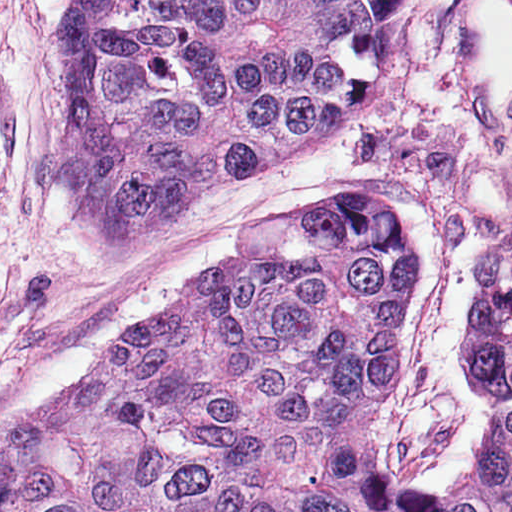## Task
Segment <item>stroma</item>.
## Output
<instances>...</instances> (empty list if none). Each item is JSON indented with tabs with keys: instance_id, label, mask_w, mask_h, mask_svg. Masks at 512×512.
<instances>
[{
	"instance_id": "obj_1",
	"label": "stroma",
	"mask_w": 512,
	"mask_h": 512,
	"mask_svg": "<svg viewBox=\"0 0 512 512\" xmlns=\"http://www.w3.org/2000/svg\"><path fill=\"white\" fill-rule=\"evenodd\" d=\"M72 0H0V429L59 398L123 329L173 300L240 225L327 190L389 201L420 247V286L374 426L411 493L464 485L496 408L359 102L299 162L216 188L152 238L112 231L61 184L63 76L52 64Z\"/></svg>"
}]
</instances>
